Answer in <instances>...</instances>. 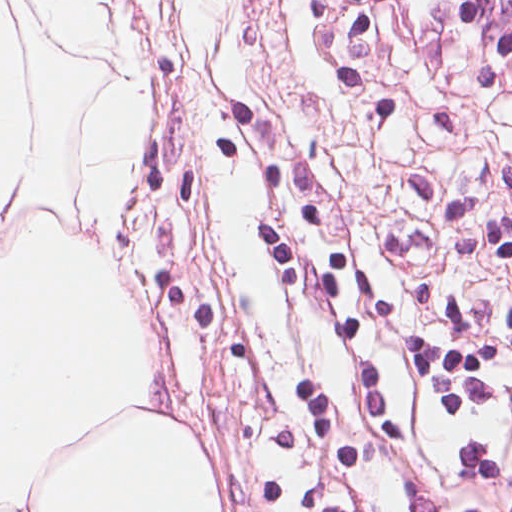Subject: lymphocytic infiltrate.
Returning <instances> with one entry per match:
<instances>
[{
	"label": "lymphocytic infiltrate",
	"mask_w": 512,
	"mask_h": 512,
	"mask_svg": "<svg viewBox=\"0 0 512 512\" xmlns=\"http://www.w3.org/2000/svg\"><path fill=\"white\" fill-rule=\"evenodd\" d=\"M495 512H512V437Z\"/></svg>",
	"instance_id": "obj_1"
}]
</instances>
